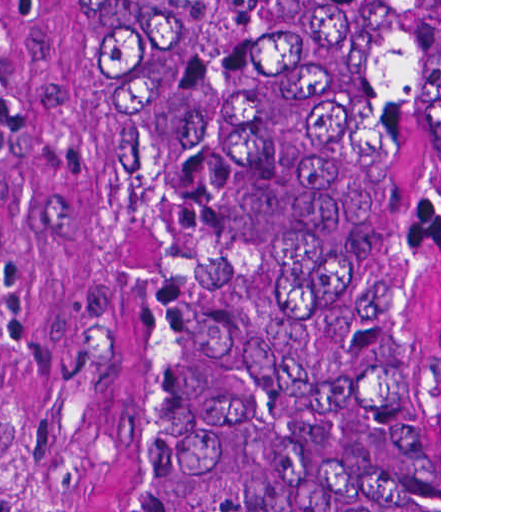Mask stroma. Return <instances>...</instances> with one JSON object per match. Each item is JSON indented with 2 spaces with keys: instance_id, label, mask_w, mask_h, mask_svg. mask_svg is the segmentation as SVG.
Wrapping results in <instances>:
<instances>
[{
  "instance_id": "obj_1",
  "label": "stroma",
  "mask_w": 512,
  "mask_h": 512,
  "mask_svg": "<svg viewBox=\"0 0 512 512\" xmlns=\"http://www.w3.org/2000/svg\"><path fill=\"white\" fill-rule=\"evenodd\" d=\"M72 1L0 0V512H49L56 461L111 341L103 138L72 79Z\"/></svg>"
}]
</instances>
